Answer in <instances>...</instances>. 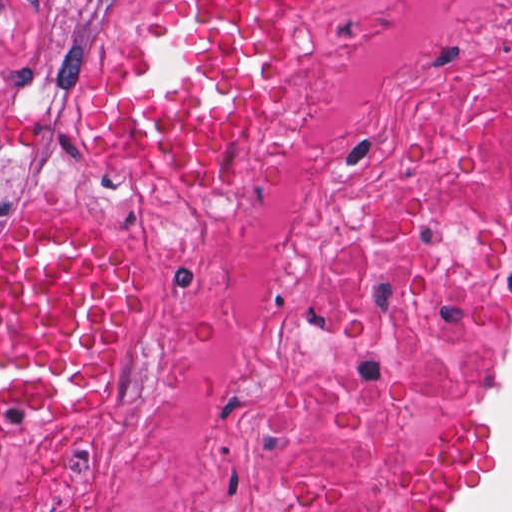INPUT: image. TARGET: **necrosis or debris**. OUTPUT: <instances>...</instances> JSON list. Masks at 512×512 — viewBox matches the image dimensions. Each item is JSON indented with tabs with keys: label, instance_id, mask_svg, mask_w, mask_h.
<instances>
[{
	"label": "necrosis or debris",
	"instance_id": "4bbe7bcc",
	"mask_svg": "<svg viewBox=\"0 0 512 512\" xmlns=\"http://www.w3.org/2000/svg\"><path fill=\"white\" fill-rule=\"evenodd\" d=\"M512 274V0H339L144 348L0 512H416Z\"/></svg>",
	"mask_w": 512,
	"mask_h": 512
}]
</instances>
